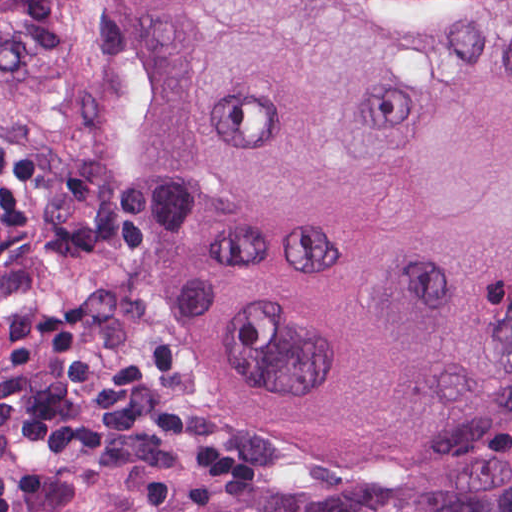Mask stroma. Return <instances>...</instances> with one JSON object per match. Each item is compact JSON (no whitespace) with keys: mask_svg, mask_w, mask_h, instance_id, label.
<instances>
[{"mask_svg":"<svg viewBox=\"0 0 512 512\" xmlns=\"http://www.w3.org/2000/svg\"><path fill=\"white\" fill-rule=\"evenodd\" d=\"M150 145L151 55L143 4L138 0L113 53L105 102V172L95 217L77 262L43 304L92 299L111 302L114 343L128 349L153 335L162 334L169 341L149 301L139 267V215ZM18 325L0 337V350ZM184 373L185 379L159 397L188 411L196 428L227 437L251 461L250 481L214 483L184 473H123L92 480L84 496L58 509L34 510L19 504L10 512H78L112 491L152 488L373 494L393 485L415 465L512 431V412H507L399 464L329 465L274 436L239 410L214 404ZM14 463L60 466L15 437L6 423L0 393V466Z\"/></svg>","mask_w":512,"mask_h":512,"instance_id":"stroma-1","label":"stroma"}]
</instances>
